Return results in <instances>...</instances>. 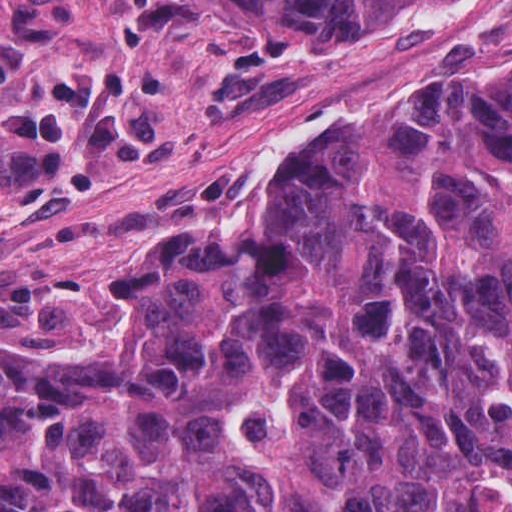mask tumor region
Segmentation results:
<instances>
[{"mask_svg": "<svg viewBox=\"0 0 512 512\" xmlns=\"http://www.w3.org/2000/svg\"><path fill=\"white\" fill-rule=\"evenodd\" d=\"M199 1L271 57L450 0ZM128 279L118 349L1 342V512H512V56Z\"/></svg>", "mask_w": 512, "mask_h": 512, "instance_id": "1", "label": "tumor region"}]
</instances>
